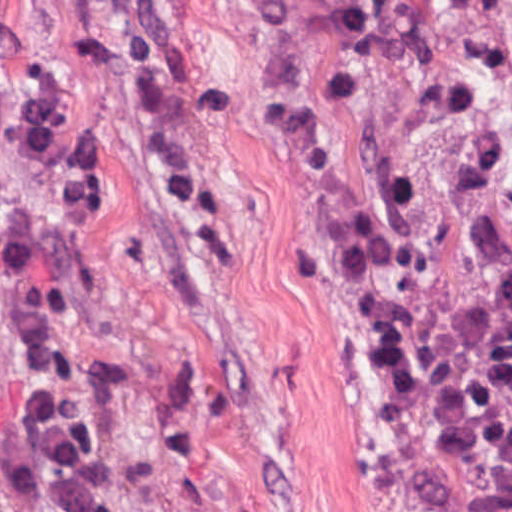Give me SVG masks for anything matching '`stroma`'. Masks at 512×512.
I'll list each match as a JSON object with an SVG mask.
<instances>
[{"label":"stroma","instance_id":"1","mask_svg":"<svg viewBox=\"0 0 512 512\" xmlns=\"http://www.w3.org/2000/svg\"><path fill=\"white\" fill-rule=\"evenodd\" d=\"M251 266L195 286L52 0H0V373L81 401L138 512H391L346 235L278 0H224ZM512 199V0H461Z\"/></svg>","mask_w":512,"mask_h":512}]
</instances>
